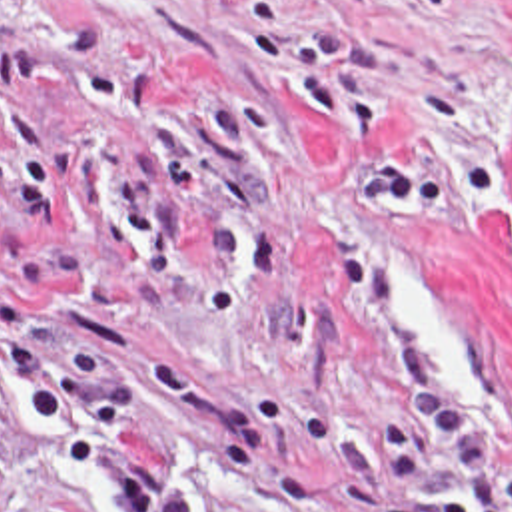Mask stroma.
<instances>
[{"instance_id": "obj_1", "label": "stroma", "mask_w": 512, "mask_h": 512, "mask_svg": "<svg viewBox=\"0 0 512 512\" xmlns=\"http://www.w3.org/2000/svg\"><path fill=\"white\" fill-rule=\"evenodd\" d=\"M404 321L512 476V0H0V512H336Z\"/></svg>"}]
</instances>
